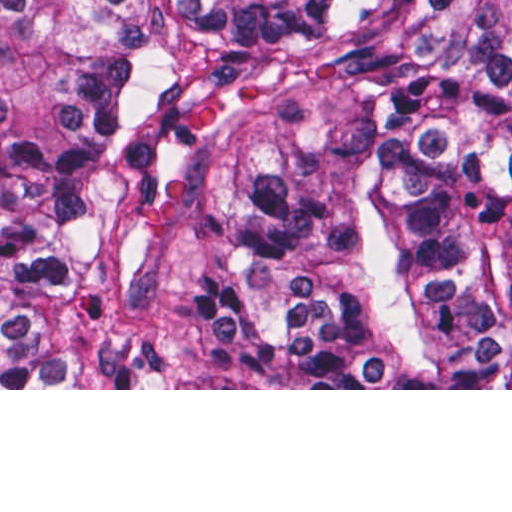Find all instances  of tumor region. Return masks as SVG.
<instances>
[{
	"label": "tumor region",
	"mask_w": 512,
	"mask_h": 512,
	"mask_svg": "<svg viewBox=\"0 0 512 512\" xmlns=\"http://www.w3.org/2000/svg\"><path fill=\"white\" fill-rule=\"evenodd\" d=\"M0 389H512V0H0Z\"/></svg>",
	"instance_id": "e687c5a6"
}]
</instances>
